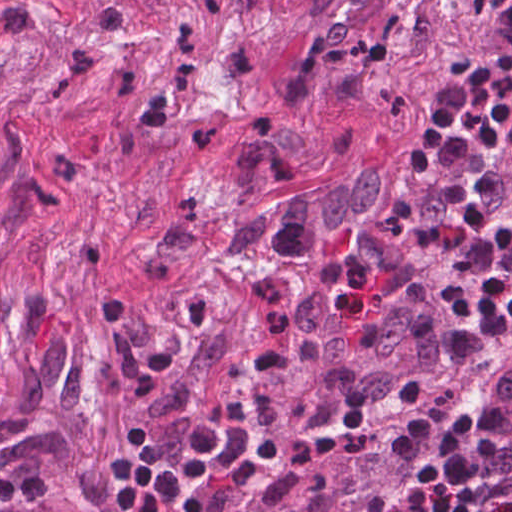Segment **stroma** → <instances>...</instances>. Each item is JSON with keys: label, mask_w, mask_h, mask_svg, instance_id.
I'll return each mask as SVG.
<instances>
[{"label": "stroma", "mask_w": 512, "mask_h": 512, "mask_svg": "<svg viewBox=\"0 0 512 512\" xmlns=\"http://www.w3.org/2000/svg\"><path fill=\"white\" fill-rule=\"evenodd\" d=\"M307 349L310 358V341ZM264 393L284 402L323 435L400 419L412 425L409 406L384 413H342L312 362L310 367L305 347ZM437 394L458 411L476 405L498 410L503 417L500 475L507 489L512 491V325L500 329L488 349L475 361L461 367Z\"/></svg>", "instance_id": "obj_1"}]
</instances>
